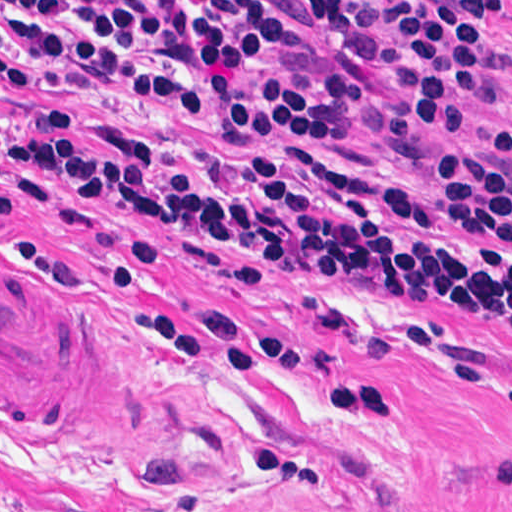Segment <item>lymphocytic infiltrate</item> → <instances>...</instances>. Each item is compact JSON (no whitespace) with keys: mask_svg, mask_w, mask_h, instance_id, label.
Listing matches in <instances>:
<instances>
[{"mask_svg":"<svg viewBox=\"0 0 512 512\" xmlns=\"http://www.w3.org/2000/svg\"><path fill=\"white\" fill-rule=\"evenodd\" d=\"M302 29L355 31L347 0H289ZM401 64L391 141L469 125L509 47L493 38L503 0H375ZM282 49L260 0L54 3L0 0V82L16 89L103 81L198 110L214 148H161L65 117L32 126L7 155L29 200L48 183L79 203L134 216V250L156 258L158 228L190 257L239 277L272 264L360 277L404 298L512 328V97L470 150L420 182L367 176L322 157L353 136L365 80L331 68L308 82L256 75ZM0 214L17 223L0 189Z\"/></svg>","mask_w":512,"mask_h":512,"instance_id":"f902f5d3","label":"lymphocytic infiltrate"}]
</instances>
